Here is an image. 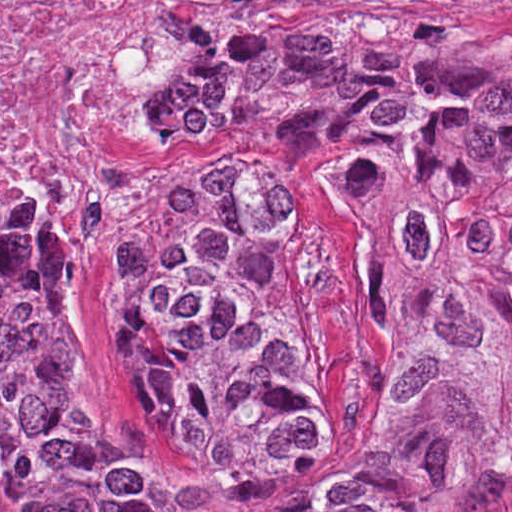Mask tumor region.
I'll use <instances>...</instances> for the list:
<instances>
[{"label":"tumor region","instance_id":"1","mask_svg":"<svg viewBox=\"0 0 512 512\" xmlns=\"http://www.w3.org/2000/svg\"><path fill=\"white\" fill-rule=\"evenodd\" d=\"M125 287L187 483L334 397L312 259L261 170L222 147L356 161L348 214L399 287L393 430L317 512H464L512 476V32L345 2L206 31ZM91 342L58 258L1 212V512H268L120 468L86 432Z\"/></svg>","mask_w":512,"mask_h":512}]
</instances>
